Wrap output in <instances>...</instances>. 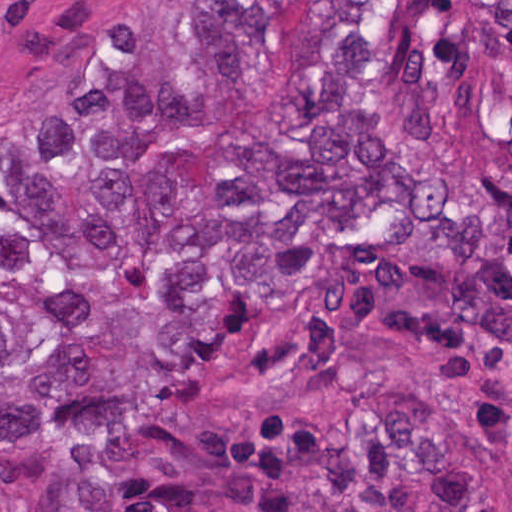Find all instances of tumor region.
<instances>
[{"label": "tumor region", "instance_id": "tumor-region-1", "mask_svg": "<svg viewBox=\"0 0 512 512\" xmlns=\"http://www.w3.org/2000/svg\"><path fill=\"white\" fill-rule=\"evenodd\" d=\"M118 8L0 118V443L54 451L34 512H492L409 389L200 403L248 319L405 234L512 343V1Z\"/></svg>", "mask_w": 512, "mask_h": 512}]
</instances>
